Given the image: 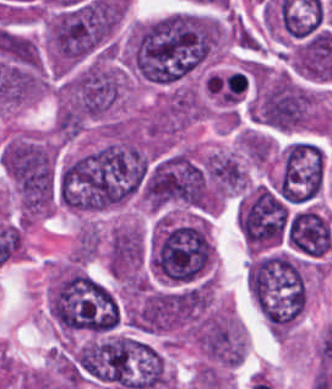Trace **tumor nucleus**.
<instances>
[{
    "mask_svg": "<svg viewBox=\"0 0 332 389\" xmlns=\"http://www.w3.org/2000/svg\"><path fill=\"white\" fill-rule=\"evenodd\" d=\"M224 38L213 16L176 12L134 27L127 63L148 82L170 85L218 53Z\"/></svg>",
    "mask_w": 332,
    "mask_h": 389,
    "instance_id": "2f306a5c",
    "label": "tumor nucleus"
},
{
    "mask_svg": "<svg viewBox=\"0 0 332 389\" xmlns=\"http://www.w3.org/2000/svg\"><path fill=\"white\" fill-rule=\"evenodd\" d=\"M138 197L153 209L213 211L216 205L204 158L186 146L165 152L145 166Z\"/></svg>",
    "mask_w": 332,
    "mask_h": 389,
    "instance_id": "8643909e",
    "label": "tumor nucleus"
},
{
    "mask_svg": "<svg viewBox=\"0 0 332 389\" xmlns=\"http://www.w3.org/2000/svg\"><path fill=\"white\" fill-rule=\"evenodd\" d=\"M246 283L267 318L298 319L304 311L306 275L297 254L285 249L256 254L247 265Z\"/></svg>",
    "mask_w": 332,
    "mask_h": 389,
    "instance_id": "5ab6c2c4",
    "label": "tumor nucleus"
},
{
    "mask_svg": "<svg viewBox=\"0 0 332 389\" xmlns=\"http://www.w3.org/2000/svg\"><path fill=\"white\" fill-rule=\"evenodd\" d=\"M256 124L282 131L325 130L327 115L319 94L289 75H270L250 100Z\"/></svg>",
    "mask_w": 332,
    "mask_h": 389,
    "instance_id": "2cbd58db",
    "label": "tumor nucleus"
},
{
    "mask_svg": "<svg viewBox=\"0 0 332 389\" xmlns=\"http://www.w3.org/2000/svg\"><path fill=\"white\" fill-rule=\"evenodd\" d=\"M122 81L116 60L91 58L63 77L56 92L57 107L85 120L105 118L121 96Z\"/></svg>",
    "mask_w": 332,
    "mask_h": 389,
    "instance_id": "3d1891a8",
    "label": "tumor nucleus"
},
{
    "mask_svg": "<svg viewBox=\"0 0 332 389\" xmlns=\"http://www.w3.org/2000/svg\"><path fill=\"white\" fill-rule=\"evenodd\" d=\"M4 171L24 201H53L57 149L46 136L18 133L1 149Z\"/></svg>",
    "mask_w": 332,
    "mask_h": 389,
    "instance_id": "2083b535",
    "label": "tumor nucleus"
},
{
    "mask_svg": "<svg viewBox=\"0 0 332 389\" xmlns=\"http://www.w3.org/2000/svg\"><path fill=\"white\" fill-rule=\"evenodd\" d=\"M191 334L204 362L227 367L242 362L246 350L245 334L231 314L207 312Z\"/></svg>",
    "mask_w": 332,
    "mask_h": 389,
    "instance_id": "8087334f",
    "label": "tumor nucleus"
},
{
    "mask_svg": "<svg viewBox=\"0 0 332 389\" xmlns=\"http://www.w3.org/2000/svg\"><path fill=\"white\" fill-rule=\"evenodd\" d=\"M203 169L215 196L237 193L246 179V171L235 152H209Z\"/></svg>",
    "mask_w": 332,
    "mask_h": 389,
    "instance_id": "c2bd9aea",
    "label": "tumor nucleus"
},
{
    "mask_svg": "<svg viewBox=\"0 0 332 389\" xmlns=\"http://www.w3.org/2000/svg\"><path fill=\"white\" fill-rule=\"evenodd\" d=\"M239 143L244 155L254 164L262 166L271 156L273 143L270 137L257 130L244 129Z\"/></svg>",
    "mask_w": 332,
    "mask_h": 389,
    "instance_id": "feef74b5",
    "label": "tumor nucleus"
}]
</instances>
